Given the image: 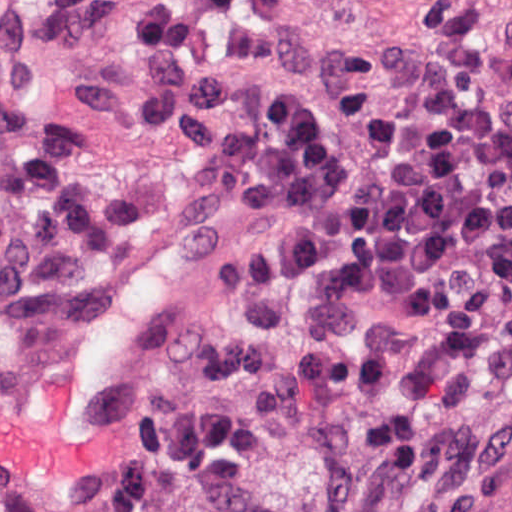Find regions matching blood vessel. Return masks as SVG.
<instances>
[{
  "instance_id": "blood-vessel-1",
  "label": "blood vessel",
  "mask_w": 512,
  "mask_h": 512,
  "mask_svg": "<svg viewBox=\"0 0 512 512\" xmlns=\"http://www.w3.org/2000/svg\"><path fill=\"white\" fill-rule=\"evenodd\" d=\"M178 0H0V24L41 22L38 53L137 33L146 6ZM60 114L84 124V165L148 210L20 352L0 361V496L84 505L122 451L135 383L161 327L204 289L214 201L191 160L159 148L114 83L82 88Z\"/></svg>"
}]
</instances>
